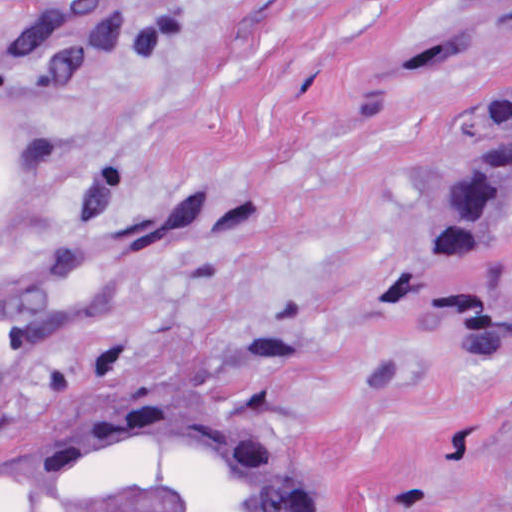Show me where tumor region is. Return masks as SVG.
I'll use <instances>...</instances> for the list:
<instances>
[{
  "instance_id": "1",
  "label": "tumor region",
  "mask_w": 512,
  "mask_h": 512,
  "mask_svg": "<svg viewBox=\"0 0 512 512\" xmlns=\"http://www.w3.org/2000/svg\"><path fill=\"white\" fill-rule=\"evenodd\" d=\"M512 19V0H481ZM512 211V98L446 167L414 259L396 277L409 328L420 284ZM437 333L512 338V283L475 297ZM7 512H315L297 475L213 412L118 409L86 424L48 479Z\"/></svg>"
}]
</instances>
